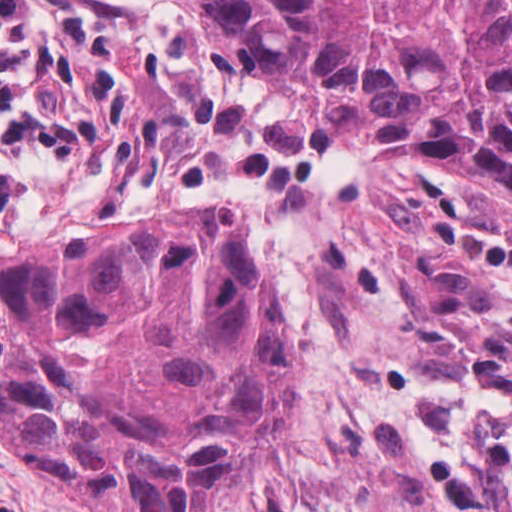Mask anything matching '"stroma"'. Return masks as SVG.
Segmentation results:
<instances>
[{"label":"stroma","mask_w":512,"mask_h":512,"mask_svg":"<svg viewBox=\"0 0 512 512\" xmlns=\"http://www.w3.org/2000/svg\"><path fill=\"white\" fill-rule=\"evenodd\" d=\"M37 93L81 136L0 259L161 209L237 212L297 325L290 420L211 512H512V205L338 133L176 0H33ZM18 512H112L0 445Z\"/></svg>","instance_id":"35a3bbf8"}]
</instances>
